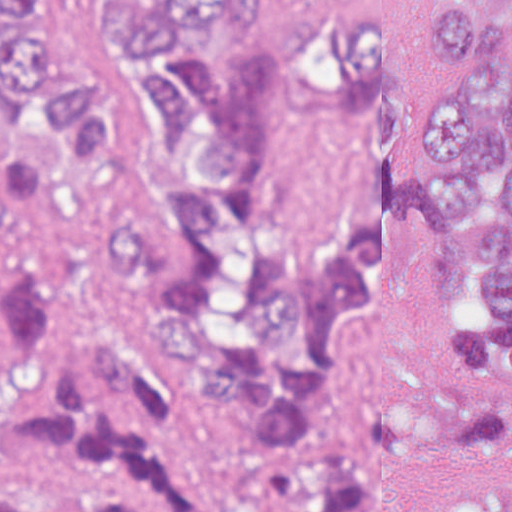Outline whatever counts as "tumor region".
Masks as SVG:
<instances>
[{
  "label": "tumor region",
  "instance_id": "obj_1",
  "mask_svg": "<svg viewBox=\"0 0 512 512\" xmlns=\"http://www.w3.org/2000/svg\"><path fill=\"white\" fill-rule=\"evenodd\" d=\"M423 53L411 123L381 0H0V182L140 202L101 234L105 275L156 303L221 428L325 427L410 216L447 226L472 318L439 339L447 402H384L235 475L0 192V512H382L443 452L512 446V0H437ZM454 512H512V489Z\"/></svg>",
  "mask_w": 512,
  "mask_h": 512
}]
</instances>
